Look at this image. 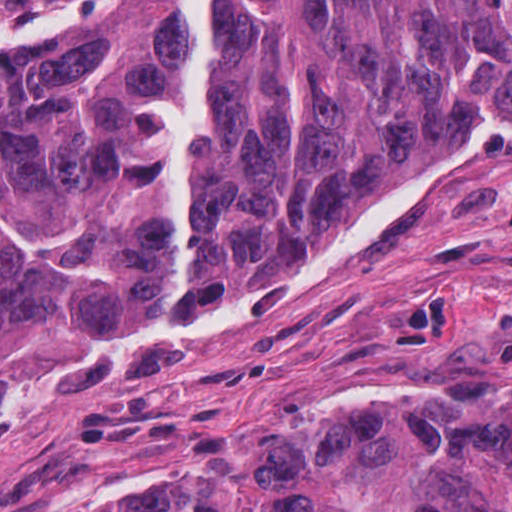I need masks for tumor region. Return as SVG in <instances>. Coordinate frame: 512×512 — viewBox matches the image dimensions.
<instances>
[{
  "label": "tumor region",
  "instance_id": "e687c5a6",
  "mask_svg": "<svg viewBox=\"0 0 512 512\" xmlns=\"http://www.w3.org/2000/svg\"><path fill=\"white\" fill-rule=\"evenodd\" d=\"M510 216L512 0H0V432L279 304L482 274ZM122 512H512V401L324 406Z\"/></svg>",
  "mask_w": 512,
  "mask_h": 512
}]
</instances>
